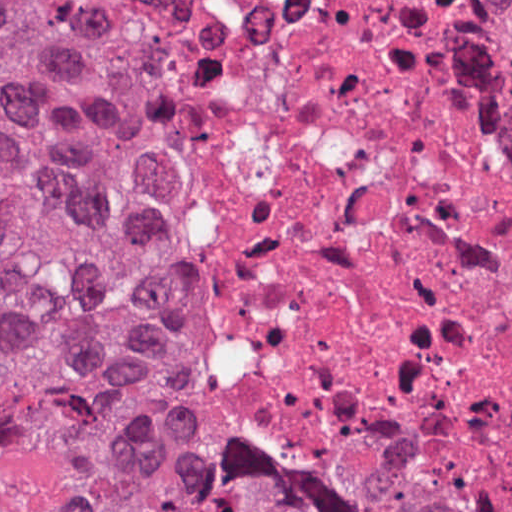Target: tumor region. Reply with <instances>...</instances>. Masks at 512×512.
I'll return each mask as SVG.
<instances>
[{
  "instance_id": "obj_1",
  "label": "tumor region",
  "mask_w": 512,
  "mask_h": 512,
  "mask_svg": "<svg viewBox=\"0 0 512 512\" xmlns=\"http://www.w3.org/2000/svg\"><path fill=\"white\" fill-rule=\"evenodd\" d=\"M0 512H394L198 437L153 312L139 128L32 1H0Z\"/></svg>"
}]
</instances>
